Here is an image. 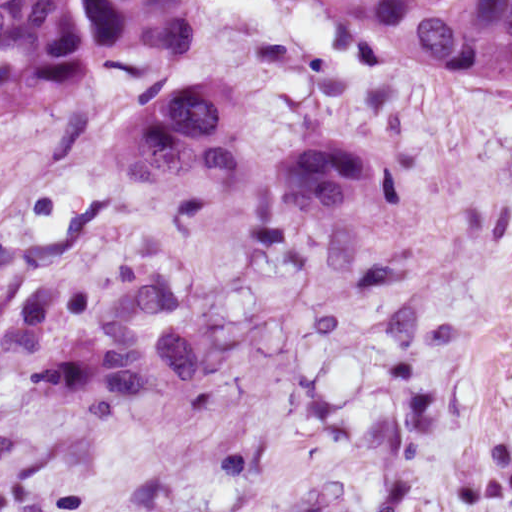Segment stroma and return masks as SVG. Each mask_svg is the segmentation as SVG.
<instances>
[{
    "label": "stroma",
    "mask_w": 512,
    "mask_h": 512,
    "mask_svg": "<svg viewBox=\"0 0 512 512\" xmlns=\"http://www.w3.org/2000/svg\"><path fill=\"white\" fill-rule=\"evenodd\" d=\"M212 49L314 134L373 125L384 176L323 215L271 204L237 162L136 181L78 103L0 125V480L512 252V76L377 64L350 24L223 0ZM172 286L206 381L111 403L42 365L127 294Z\"/></svg>",
    "instance_id": "35a3bbf8"
}]
</instances>
